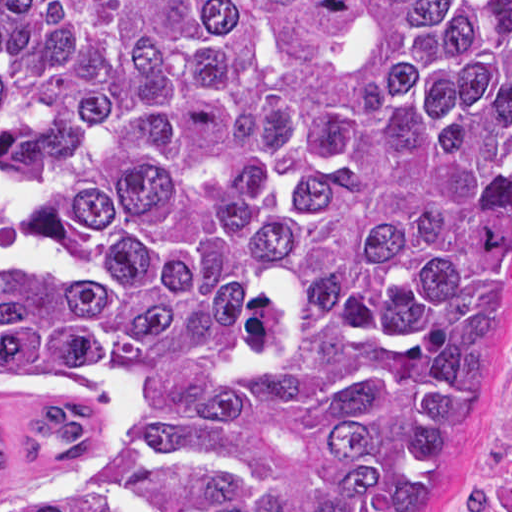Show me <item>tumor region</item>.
<instances>
[{
  "mask_svg": "<svg viewBox=\"0 0 512 512\" xmlns=\"http://www.w3.org/2000/svg\"><path fill=\"white\" fill-rule=\"evenodd\" d=\"M512 378V0H0V512H436Z\"/></svg>",
  "mask_w": 512,
  "mask_h": 512,
  "instance_id": "obj_1",
  "label": "tumor region"
}]
</instances>
